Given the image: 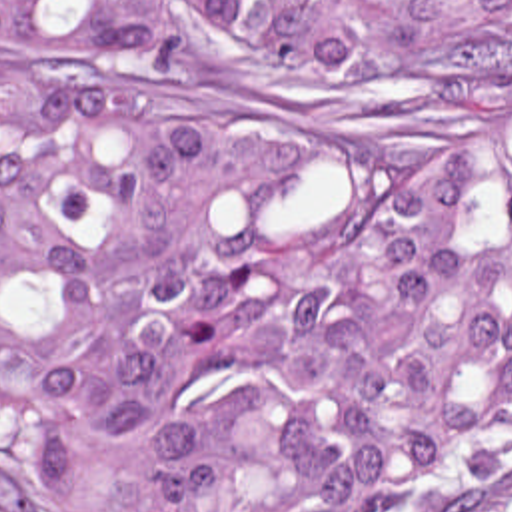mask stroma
Listing matches in <instances>:
<instances>
[{
  "mask_svg": "<svg viewBox=\"0 0 512 512\" xmlns=\"http://www.w3.org/2000/svg\"><path fill=\"white\" fill-rule=\"evenodd\" d=\"M0 54H6V52H0ZM0 512H12L8 501H6L4 481H2V425H0Z\"/></svg>",
  "mask_w": 512,
  "mask_h": 512,
  "instance_id": "stroma-1",
  "label": "stroma"
}]
</instances>
